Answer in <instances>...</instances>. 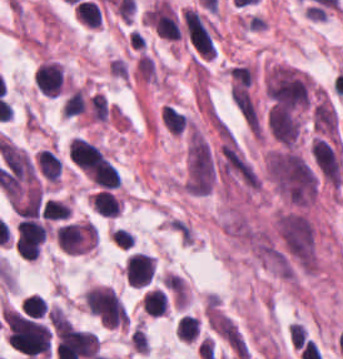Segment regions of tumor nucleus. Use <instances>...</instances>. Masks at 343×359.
<instances>
[{
    "mask_svg": "<svg viewBox=\"0 0 343 359\" xmlns=\"http://www.w3.org/2000/svg\"><path fill=\"white\" fill-rule=\"evenodd\" d=\"M301 108L268 98L264 128L279 143H294L300 128Z\"/></svg>",
    "mask_w": 343,
    "mask_h": 359,
    "instance_id": "4",
    "label": "tumor nucleus"
},
{
    "mask_svg": "<svg viewBox=\"0 0 343 359\" xmlns=\"http://www.w3.org/2000/svg\"><path fill=\"white\" fill-rule=\"evenodd\" d=\"M310 121L315 133L335 136L338 121L333 107L324 101L313 103L310 110Z\"/></svg>",
    "mask_w": 343,
    "mask_h": 359,
    "instance_id": "7",
    "label": "tumor nucleus"
},
{
    "mask_svg": "<svg viewBox=\"0 0 343 359\" xmlns=\"http://www.w3.org/2000/svg\"><path fill=\"white\" fill-rule=\"evenodd\" d=\"M309 151L318 176L339 186L343 173V160L337 143L329 137L314 133Z\"/></svg>",
    "mask_w": 343,
    "mask_h": 359,
    "instance_id": "5",
    "label": "tumor nucleus"
},
{
    "mask_svg": "<svg viewBox=\"0 0 343 359\" xmlns=\"http://www.w3.org/2000/svg\"><path fill=\"white\" fill-rule=\"evenodd\" d=\"M275 225L285 255L314 256V231L301 213L284 212L277 217Z\"/></svg>",
    "mask_w": 343,
    "mask_h": 359,
    "instance_id": "3",
    "label": "tumor nucleus"
},
{
    "mask_svg": "<svg viewBox=\"0 0 343 359\" xmlns=\"http://www.w3.org/2000/svg\"><path fill=\"white\" fill-rule=\"evenodd\" d=\"M268 174L290 203L307 205L315 196V177L305 159L290 150L269 153Z\"/></svg>",
    "mask_w": 343,
    "mask_h": 359,
    "instance_id": "1",
    "label": "tumor nucleus"
},
{
    "mask_svg": "<svg viewBox=\"0 0 343 359\" xmlns=\"http://www.w3.org/2000/svg\"><path fill=\"white\" fill-rule=\"evenodd\" d=\"M264 91L275 107H308V81L303 73L291 67L269 69Z\"/></svg>",
    "mask_w": 343,
    "mask_h": 359,
    "instance_id": "2",
    "label": "tumor nucleus"
},
{
    "mask_svg": "<svg viewBox=\"0 0 343 359\" xmlns=\"http://www.w3.org/2000/svg\"><path fill=\"white\" fill-rule=\"evenodd\" d=\"M206 324L209 330L240 359H246L248 350L245 339L233 319L211 307L206 316Z\"/></svg>",
    "mask_w": 343,
    "mask_h": 359,
    "instance_id": "6",
    "label": "tumor nucleus"
}]
</instances>
